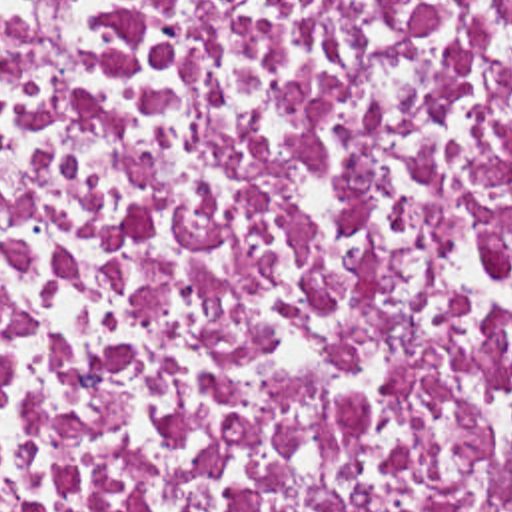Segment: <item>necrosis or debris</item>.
Wrapping results in <instances>:
<instances>
[{"mask_svg":"<svg viewBox=\"0 0 512 512\" xmlns=\"http://www.w3.org/2000/svg\"><path fill=\"white\" fill-rule=\"evenodd\" d=\"M0 512H512V0H0Z\"/></svg>","mask_w":512,"mask_h":512,"instance_id":"obj_1","label":"necrosis or debris"}]
</instances>
